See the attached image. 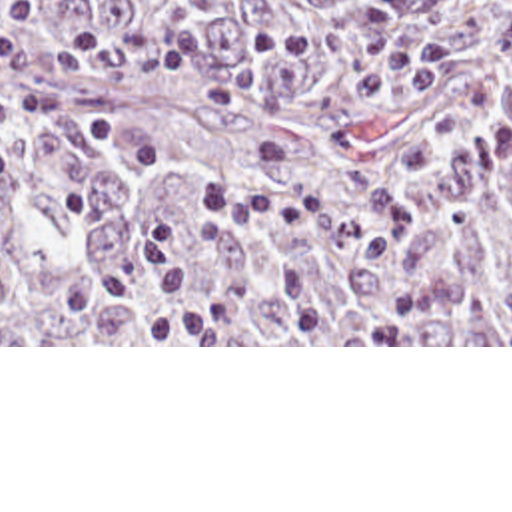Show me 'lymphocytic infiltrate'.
I'll return each instance as SVG.
<instances>
[{"instance_id":"1","label":"lymphocytic infiltrate","mask_w":512,"mask_h":512,"mask_svg":"<svg viewBox=\"0 0 512 512\" xmlns=\"http://www.w3.org/2000/svg\"><path fill=\"white\" fill-rule=\"evenodd\" d=\"M36 8L12 2L0 10V81L24 67L54 71L124 67L157 71L167 79H193L199 101L217 111L237 109V91L215 75L209 65L211 40L197 24L153 28L138 36H120L108 26L74 24L46 44L12 38L28 26ZM12 101L0 97V123L10 115ZM12 165V147L0 139V171Z\"/></svg>"}]
</instances>
